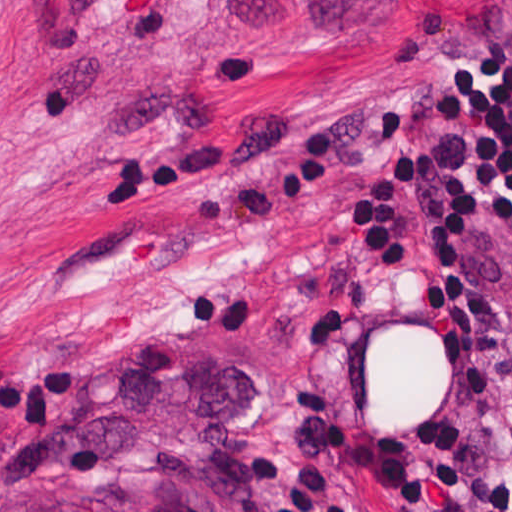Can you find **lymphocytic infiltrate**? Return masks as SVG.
<instances>
[{"label": "lymphocytic infiltrate", "mask_w": 512, "mask_h": 512, "mask_svg": "<svg viewBox=\"0 0 512 512\" xmlns=\"http://www.w3.org/2000/svg\"><path fill=\"white\" fill-rule=\"evenodd\" d=\"M420 108L452 133L445 153L415 141L401 112L379 113L375 145L342 183L344 224L366 256L420 278L413 240L425 200L433 236L424 293L435 307L449 391L424 410L420 426L379 444V463L400 507L419 504L434 487L453 512H512V470L475 453L495 391L512 451V356L473 276L479 238L512 232V56L465 47L429 78Z\"/></svg>", "instance_id": "obj_1"}]
</instances>
